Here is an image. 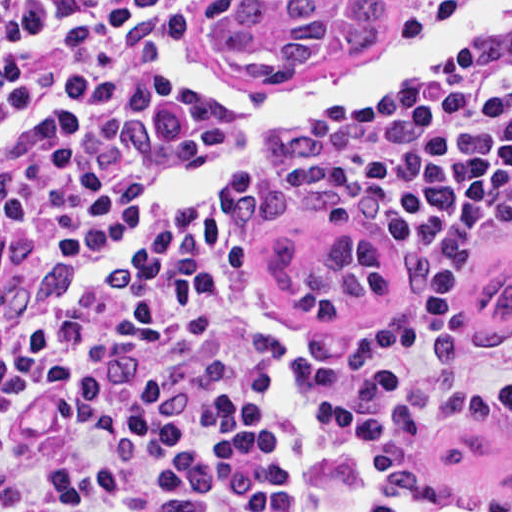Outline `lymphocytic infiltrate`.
Wrapping results in <instances>:
<instances>
[{
	"instance_id": "obj_1",
	"label": "lymphocytic infiltrate",
	"mask_w": 512,
	"mask_h": 512,
	"mask_svg": "<svg viewBox=\"0 0 512 512\" xmlns=\"http://www.w3.org/2000/svg\"><path fill=\"white\" fill-rule=\"evenodd\" d=\"M198 0H0V512H364L512 414V55L311 139L285 193L416 247L390 337L307 355L236 204L106 241L220 125L161 50ZM70 264L52 284L53 269Z\"/></svg>"
}]
</instances>
